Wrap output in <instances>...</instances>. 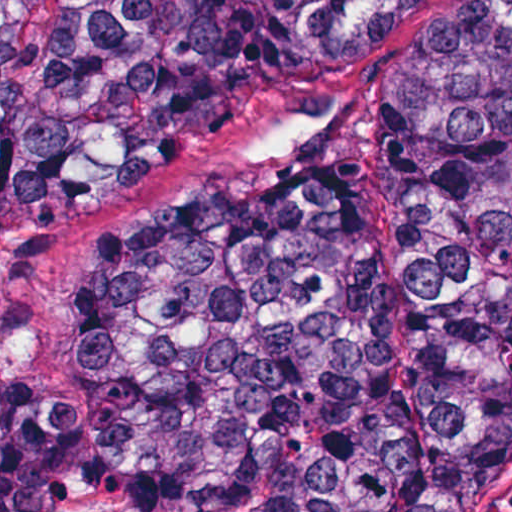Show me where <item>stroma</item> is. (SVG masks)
<instances>
[{"label":"stroma","mask_w":512,"mask_h":512,"mask_svg":"<svg viewBox=\"0 0 512 512\" xmlns=\"http://www.w3.org/2000/svg\"><path fill=\"white\" fill-rule=\"evenodd\" d=\"M470 1L445 0L344 64L248 108L172 163L1 243L0 379L33 395L60 386L61 330L91 233L133 225L187 193L250 187L284 151L311 140L324 143L326 161L368 167V221L396 323L406 324L383 177L389 83L395 69ZM498 512H512V494Z\"/></svg>","instance_id":"1"}]
</instances>
